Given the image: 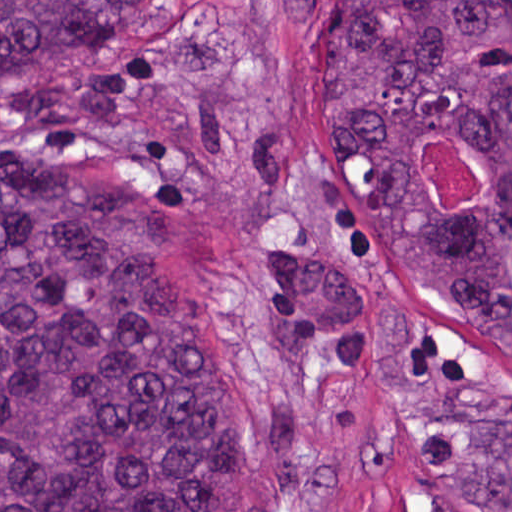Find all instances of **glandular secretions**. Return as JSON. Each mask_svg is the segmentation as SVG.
I'll return each mask as SVG.
<instances>
[{"label":"glandular secretions","instance_id":"obj_1","mask_svg":"<svg viewBox=\"0 0 512 512\" xmlns=\"http://www.w3.org/2000/svg\"><path fill=\"white\" fill-rule=\"evenodd\" d=\"M457 143H459V142H457ZM459 144L462 147H464L466 150H468L470 153H472L468 147L462 145L461 143H459ZM474 160H475V169H476V199H478L485 192V174L483 173L481 166L475 156H474ZM416 166H417V169H418L423 181L425 182L426 186L428 187L435 203L438 205V207L442 211L447 212V213H467L472 208L474 203H472L468 207L464 208L463 210H457V209L452 208L442 202L440 196L435 191V189L432 185V182L430 181V179L428 177L426 168L424 166V163L422 160V146L419 148L417 155H416Z\"/></svg>","mask_w":512,"mask_h":512}]
</instances>
